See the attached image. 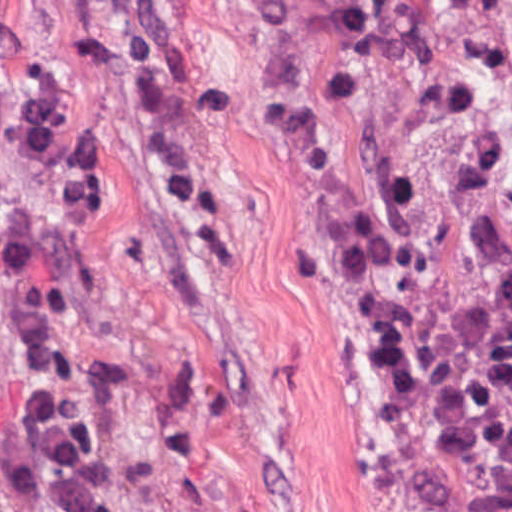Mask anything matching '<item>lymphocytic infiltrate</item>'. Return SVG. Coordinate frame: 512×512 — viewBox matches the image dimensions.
<instances>
[{
	"mask_svg": "<svg viewBox=\"0 0 512 512\" xmlns=\"http://www.w3.org/2000/svg\"><path fill=\"white\" fill-rule=\"evenodd\" d=\"M0 512H138L79 399L0 373Z\"/></svg>",
	"mask_w": 512,
	"mask_h": 512,
	"instance_id": "obj_1",
	"label": "lymphocytic infiltrate"
}]
</instances>
